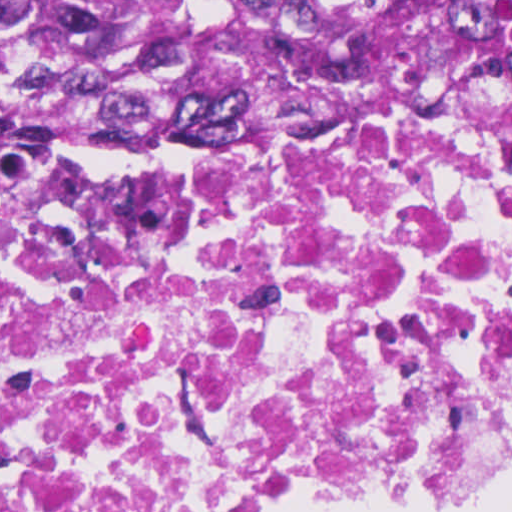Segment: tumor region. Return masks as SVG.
<instances>
[{
  "label": "tumor region",
  "instance_id": "e687c5a6",
  "mask_svg": "<svg viewBox=\"0 0 512 512\" xmlns=\"http://www.w3.org/2000/svg\"><path fill=\"white\" fill-rule=\"evenodd\" d=\"M512 89V0H0V149L88 129L235 138Z\"/></svg>",
  "mask_w": 512,
  "mask_h": 512
}]
</instances>
